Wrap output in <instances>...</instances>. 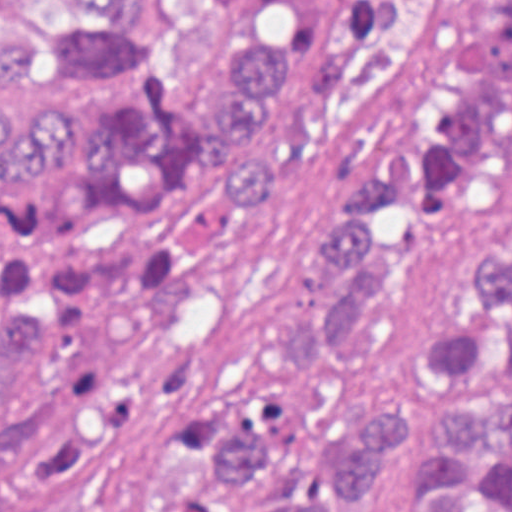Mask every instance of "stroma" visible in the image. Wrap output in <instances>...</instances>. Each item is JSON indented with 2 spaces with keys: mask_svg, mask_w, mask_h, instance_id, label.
Returning a JSON list of instances; mask_svg holds the SVG:
<instances>
[{
  "mask_svg": "<svg viewBox=\"0 0 512 512\" xmlns=\"http://www.w3.org/2000/svg\"><path fill=\"white\" fill-rule=\"evenodd\" d=\"M23 20L73 19L54 0H0V28ZM475 23L476 0H406L344 63L324 98L332 138L295 158L275 199L235 213L211 307L181 344L177 390L135 426L110 512H219L224 482L209 435L259 396L280 398L295 423L272 462L232 489V512L295 509L318 465L348 456L368 424L394 411L411 414L412 432L382 487L357 501L343 494V512H407V477L448 408L433 385L407 378L473 288L478 260L511 235L512 170L461 196L403 287L306 367L258 372L248 338L327 300L307 266L327 220L455 67ZM0 94L68 115L80 137H94L102 119L1 70Z\"/></svg>",
  "mask_w": 512,
  "mask_h": 512,
  "instance_id": "35a3bbf8",
  "label": "stroma"
}]
</instances>
